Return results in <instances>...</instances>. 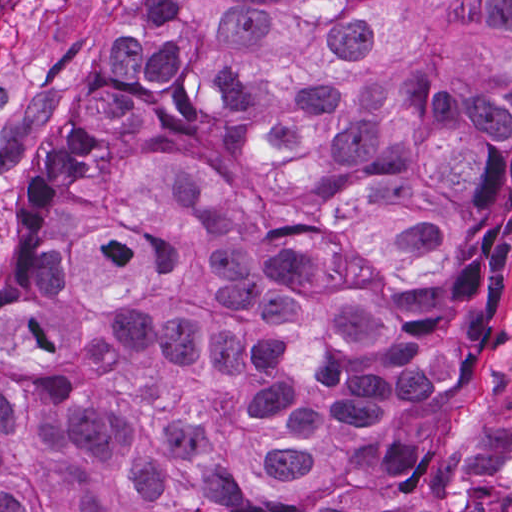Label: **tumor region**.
<instances>
[{
  "instance_id": "tumor-region-1",
  "label": "tumor region",
  "mask_w": 512,
  "mask_h": 512,
  "mask_svg": "<svg viewBox=\"0 0 512 512\" xmlns=\"http://www.w3.org/2000/svg\"><path fill=\"white\" fill-rule=\"evenodd\" d=\"M510 225L512 0H149L0 258V512H382L417 334Z\"/></svg>"
}]
</instances>
